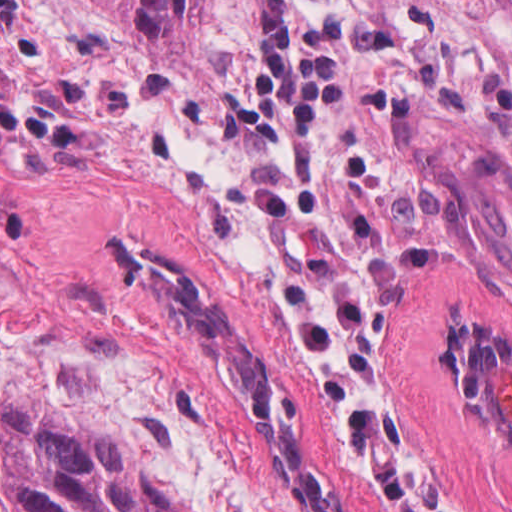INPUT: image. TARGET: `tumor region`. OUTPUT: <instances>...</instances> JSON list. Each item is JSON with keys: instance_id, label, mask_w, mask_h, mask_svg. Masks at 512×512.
<instances>
[{"instance_id": "obj_1", "label": "tumor region", "mask_w": 512, "mask_h": 512, "mask_svg": "<svg viewBox=\"0 0 512 512\" xmlns=\"http://www.w3.org/2000/svg\"><path fill=\"white\" fill-rule=\"evenodd\" d=\"M132 23L175 44H196L210 0H114ZM455 383L482 419L512 435V341L486 329L456 325Z\"/></svg>"}]
</instances>
